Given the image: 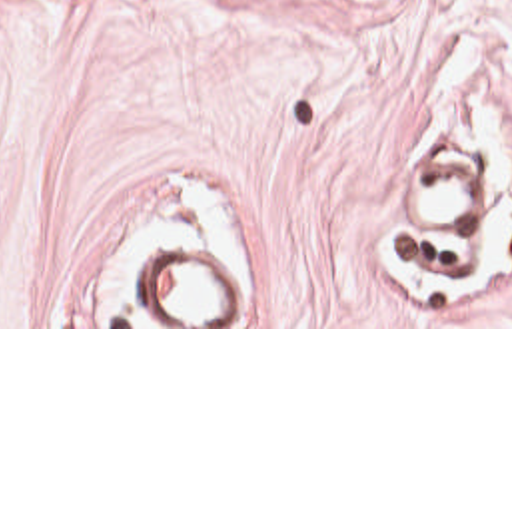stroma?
<instances>
[{"label":"stroma","mask_w":512,"mask_h":512,"mask_svg":"<svg viewBox=\"0 0 512 512\" xmlns=\"http://www.w3.org/2000/svg\"><path fill=\"white\" fill-rule=\"evenodd\" d=\"M0 329H512V0H0Z\"/></svg>","instance_id":"35a3bbf8"}]
</instances>
